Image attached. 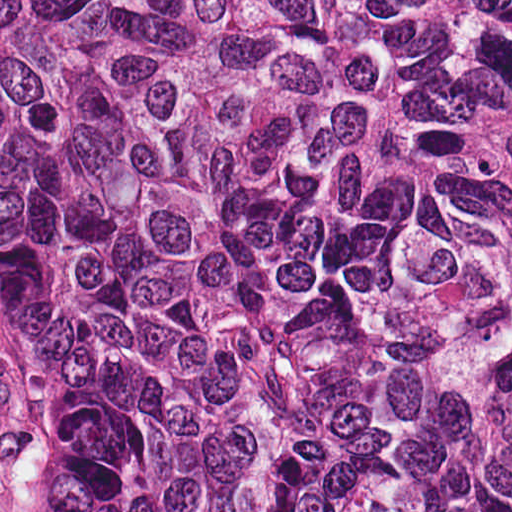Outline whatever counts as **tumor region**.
Masks as SVG:
<instances>
[{
  "label": "tumor region",
  "mask_w": 512,
  "mask_h": 512,
  "mask_svg": "<svg viewBox=\"0 0 512 512\" xmlns=\"http://www.w3.org/2000/svg\"><path fill=\"white\" fill-rule=\"evenodd\" d=\"M0 326L52 512H512V0H0Z\"/></svg>",
  "instance_id": "tumor-region-1"
}]
</instances>
